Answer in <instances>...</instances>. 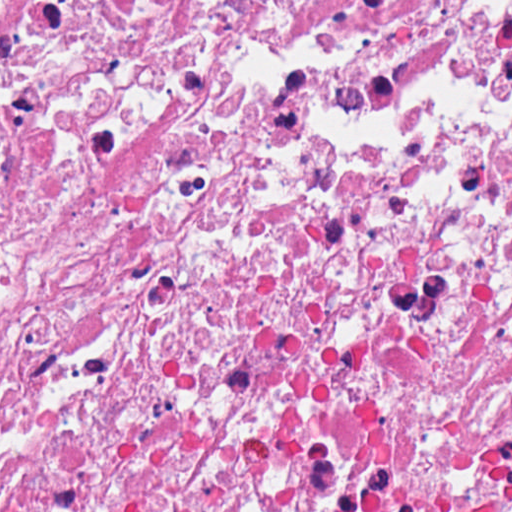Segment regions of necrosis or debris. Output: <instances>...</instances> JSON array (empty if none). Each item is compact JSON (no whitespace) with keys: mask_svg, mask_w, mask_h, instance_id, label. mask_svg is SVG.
<instances>
[{"mask_svg":"<svg viewBox=\"0 0 512 512\" xmlns=\"http://www.w3.org/2000/svg\"><path fill=\"white\" fill-rule=\"evenodd\" d=\"M0 512H512V0H0Z\"/></svg>","mask_w":512,"mask_h":512,"instance_id":"1","label":"necrosis or debris"}]
</instances>
